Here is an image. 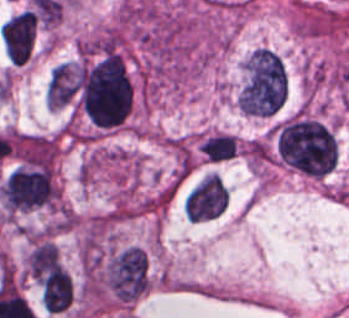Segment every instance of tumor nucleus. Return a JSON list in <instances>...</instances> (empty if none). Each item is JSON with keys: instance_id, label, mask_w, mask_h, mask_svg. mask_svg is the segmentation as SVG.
<instances>
[{"instance_id": "obj_2", "label": "tumor nucleus", "mask_w": 349, "mask_h": 318, "mask_svg": "<svg viewBox=\"0 0 349 318\" xmlns=\"http://www.w3.org/2000/svg\"><path fill=\"white\" fill-rule=\"evenodd\" d=\"M104 283L115 301L133 303L149 287V265L145 252L130 245L113 253L104 265Z\"/></svg>"}, {"instance_id": "obj_1", "label": "tumor nucleus", "mask_w": 349, "mask_h": 318, "mask_svg": "<svg viewBox=\"0 0 349 318\" xmlns=\"http://www.w3.org/2000/svg\"><path fill=\"white\" fill-rule=\"evenodd\" d=\"M281 162L297 173L321 178L338 160V143L330 128L313 116L296 114L280 123L272 135Z\"/></svg>"}, {"instance_id": "obj_4", "label": "tumor nucleus", "mask_w": 349, "mask_h": 318, "mask_svg": "<svg viewBox=\"0 0 349 318\" xmlns=\"http://www.w3.org/2000/svg\"><path fill=\"white\" fill-rule=\"evenodd\" d=\"M228 204L229 194L222 179L209 174L189 191L183 209L187 220L202 222L220 216Z\"/></svg>"}, {"instance_id": "obj_5", "label": "tumor nucleus", "mask_w": 349, "mask_h": 318, "mask_svg": "<svg viewBox=\"0 0 349 318\" xmlns=\"http://www.w3.org/2000/svg\"><path fill=\"white\" fill-rule=\"evenodd\" d=\"M82 74L80 62L61 61L50 72L46 91V104L64 107L75 99Z\"/></svg>"}, {"instance_id": "obj_3", "label": "tumor nucleus", "mask_w": 349, "mask_h": 318, "mask_svg": "<svg viewBox=\"0 0 349 318\" xmlns=\"http://www.w3.org/2000/svg\"><path fill=\"white\" fill-rule=\"evenodd\" d=\"M7 212H19L49 205L59 197V191L49 175L17 171L1 188Z\"/></svg>"}, {"instance_id": "obj_7", "label": "tumor nucleus", "mask_w": 349, "mask_h": 318, "mask_svg": "<svg viewBox=\"0 0 349 318\" xmlns=\"http://www.w3.org/2000/svg\"><path fill=\"white\" fill-rule=\"evenodd\" d=\"M237 146L233 134L215 132L203 138L199 150L210 163H221L235 156Z\"/></svg>"}, {"instance_id": "obj_6", "label": "tumor nucleus", "mask_w": 349, "mask_h": 318, "mask_svg": "<svg viewBox=\"0 0 349 318\" xmlns=\"http://www.w3.org/2000/svg\"><path fill=\"white\" fill-rule=\"evenodd\" d=\"M24 268L29 277L42 281L65 268L52 238H33L25 256Z\"/></svg>"}]
</instances>
